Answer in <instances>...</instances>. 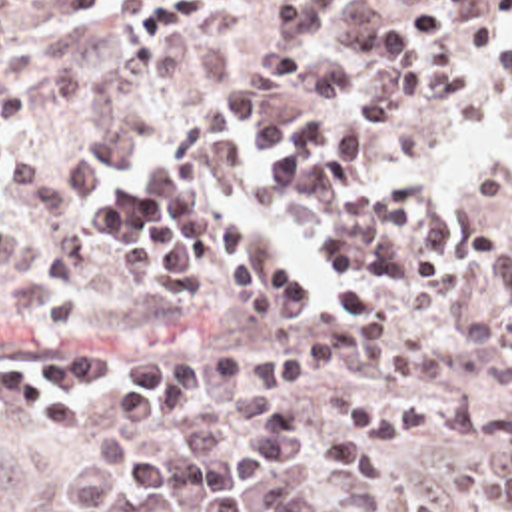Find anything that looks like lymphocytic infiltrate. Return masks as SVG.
Returning <instances> with one entry per match:
<instances>
[{"mask_svg": "<svg viewBox=\"0 0 512 512\" xmlns=\"http://www.w3.org/2000/svg\"><path fill=\"white\" fill-rule=\"evenodd\" d=\"M237 0H123L143 8L125 24L131 50H157ZM492 60L512 82V0L488 6L454 36L380 60L394 84L364 92L348 64H321L305 74L309 124L265 114L255 84L217 90L223 114L243 134V154L277 158L263 170L267 192H291L327 218L319 246L325 270L343 282L329 300L337 316L307 346L281 352H169L133 356L115 346L21 372L0 394L45 424H73L79 394L91 382L121 378L109 396L111 424H165L177 418L189 390L203 382L247 388H311L321 364L378 350L386 338V310L408 296L458 278L502 246L500 226H456L436 214L416 220L424 184L402 178L384 190L364 168L362 146L382 140L402 108H422L470 92L472 60L454 40ZM97 242L121 250V266L145 286L181 302L211 298V268L227 274L255 318L315 312V288L281 250H259L241 218L211 204L141 224H103ZM331 424L344 438L309 426L271 424L247 434H297L331 458L335 476L384 486L394 478L406 440H488L508 448L512 486V408H492L470 396H408L384 402L368 388H352L333 404Z\"/></svg>", "mask_w": 512, "mask_h": 512, "instance_id": "obj_1", "label": "lymphocytic infiltrate"}]
</instances>
